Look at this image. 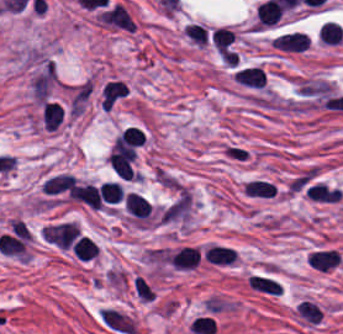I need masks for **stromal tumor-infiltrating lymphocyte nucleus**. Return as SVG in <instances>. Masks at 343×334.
Returning <instances> with one entry per match:
<instances>
[{
  "instance_id": "2",
  "label": "stromal tumor-infiltrating lymphocyte nucleus",
  "mask_w": 343,
  "mask_h": 334,
  "mask_svg": "<svg viewBox=\"0 0 343 334\" xmlns=\"http://www.w3.org/2000/svg\"><path fill=\"white\" fill-rule=\"evenodd\" d=\"M271 45L280 49L303 50L309 45V38L302 32H282L271 38Z\"/></svg>"
},
{
  "instance_id": "3",
  "label": "stromal tumor-infiltrating lymphocyte nucleus",
  "mask_w": 343,
  "mask_h": 334,
  "mask_svg": "<svg viewBox=\"0 0 343 334\" xmlns=\"http://www.w3.org/2000/svg\"><path fill=\"white\" fill-rule=\"evenodd\" d=\"M76 201L90 207L99 208L102 206L96 184L91 181H84L74 187Z\"/></svg>"
},
{
  "instance_id": "6",
  "label": "stromal tumor-infiltrating lymphocyte nucleus",
  "mask_w": 343,
  "mask_h": 334,
  "mask_svg": "<svg viewBox=\"0 0 343 334\" xmlns=\"http://www.w3.org/2000/svg\"><path fill=\"white\" fill-rule=\"evenodd\" d=\"M71 249L81 258L90 259L97 255L98 248L94 239L87 234H79L71 244Z\"/></svg>"
},
{
  "instance_id": "5",
  "label": "stromal tumor-infiltrating lymphocyte nucleus",
  "mask_w": 343,
  "mask_h": 334,
  "mask_svg": "<svg viewBox=\"0 0 343 334\" xmlns=\"http://www.w3.org/2000/svg\"><path fill=\"white\" fill-rule=\"evenodd\" d=\"M63 110L54 101H45L42 105L41 119L44 129L52 131L56 128L62 118Z\"/></svg>"
},
{
  "instance_id": "7",
  "label": "stromal tumor-infiltrating lymphocyte nucleus",
  "mask_w": 343,
  "mask_h": 334,
  "mask_svg": "<svg viewBox=\"0 0 343 334\" xmlns=\"http://www.w3.org/2000/svg\"><path fill=\"white\" fill-rule=\"evenodd\" d=\"M242 191L249 197H272L275 193L272 182L258 179L247 180Z\"/></svg>"
},
{
  "instance_id": "4",
  "label": "stromal tumor-infiltrating lymphocyte nucleus",
  "mask_w": 343,
  "mask_h": 334,
  "mask_svg": "<svg viewBox=\"0 0 343 334\" xmlns=\"http://www.w3.org/2000/svg\"><path fill=\"white\" fill-rule=\"evenodd\" d=\"M319 43L336 44L343 40V32L339 23L333 20H326L319 23L317 31Z\"/></svg>"
},
{
  "instance_id": "1",
  "label": "stromal tumor-infiltrating lymphocyte nucleus",
  "mask_w": 343,
  "mask_h": 334,
  "mask_svg": "<svg viewBox=\"0 0 343 334\" xmlns=\"http://www.w3.org/2000/svg\"><path fill=\"white\" fill-rule=\"evenodd\" d=\"M237 253L232 247L211 243L203 250L202 259L213 265H232Z\"/></svg>"
},
{
  "instance_id": "8",
  "label": "stromal tumor-infiltrating lymphocyte nucleus",
  "mask_w": 343,
  "mask_h": 334,
  "mask_svg": "<svg viewBox=\"0 0 343 334\" xmlns=\"http://www.w3.org/2000/svg\"><path fill=\"white\" fill-rule=\"evenodd\" d=\"M101 202L117 203L122 197V189L116 180H102L96 189Z\"/></svg>"
}]
</instances>
